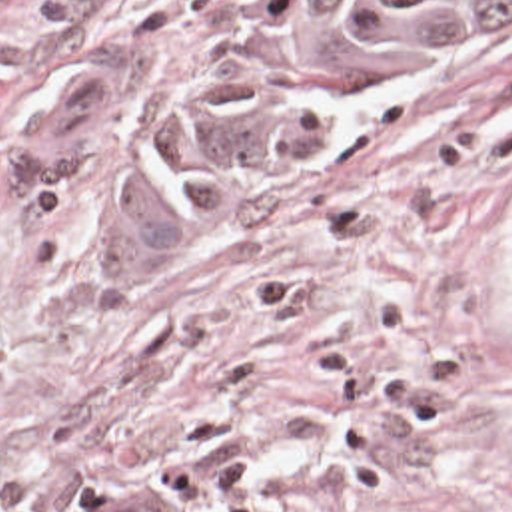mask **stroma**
<instances>
[{"label":"stroma","instance_id":"35a3bbf8","mask_svg":"<svg viewBox=\"0 0 512 512\" xmlns=\"http://www.w3.org/2000/svg\"><path fill=\"white\" fill-rule=\"evenodd\" d=\"M243 0H0V512H512V41L213 227H145L139 143ZM109 145L25 189L55 75Z\"/></svg>","mask_w":512,"mask_h":512}]
</instances>
